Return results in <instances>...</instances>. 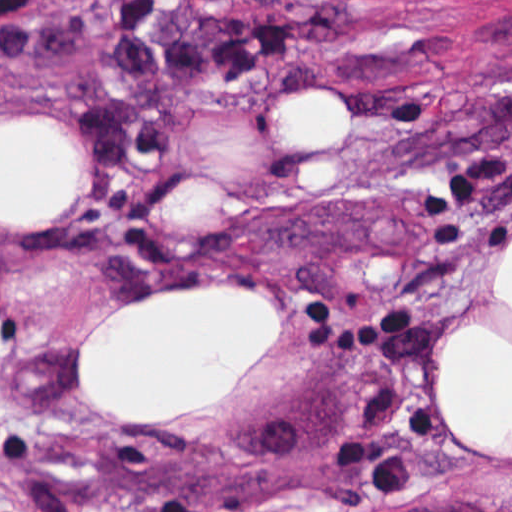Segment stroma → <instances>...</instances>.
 <instances>
[{"instance_id":"stroma-1","label":"stroma","mask_w":512,"mask_h":512,"mask_svg":"<svg viewBox=\"0 0 512 512\" xmlns=\"http://www.w3.org/2000/svg\"><path fill=\"white\" fill-rule=\"evenodd\" d=\"M116 5L16 0L0 22V121L83 149L55 215L0 226V512H512V460L431 411L437 344L512 246V0H269L344 29L172 90L165 146L108 187L77 115L124 96ZM321 79L347 141L295 151L278 114ZM160 292L274 295L278 344L205 417L119 427L78 348Z\"/></svg>"}]
</instances>
